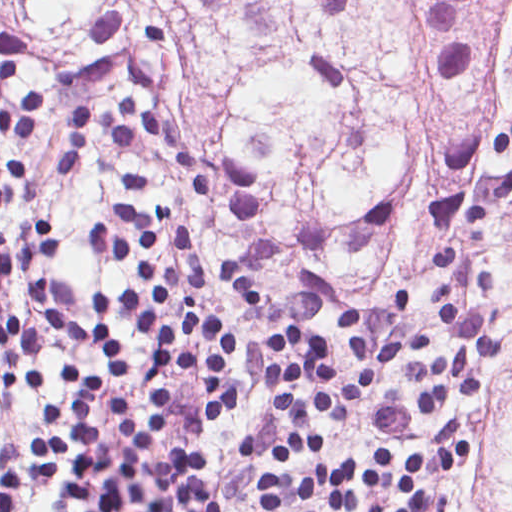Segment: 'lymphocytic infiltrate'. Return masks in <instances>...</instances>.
<instances>
[{
  "label": "lymphocytic infiltrate",
  "instance_id": "lymphocytic-infiltrate-1",
  "mask_svg": "<svg viewBox=\"0 0 512 512\" xmlns=\"http://www.w3.org/2000/svg\"><path fill=\"white\" fill-rule=\"evenodd\" d=\"M25 40L0 33V134H29L37 127L43 94L9 92L19 77ZM101 129L112 145L134 147L148 133L166 157L183 172L192 192L212 197V172L192 139L180 126L140 103L125 90L111 104L78 100L64 112L59 132V175L82 164L90 133ZM35 198V184L19 159L0 158V209ZM112 221L89 233L95 248L138 280L126 287H97L92 308V350L105 357L112 372L126 378L133 364L114 345L118 331L147 336L162 352L164 366L156 378L186 370L207 382L197 410L202 422L226 425L240 411L242 397L232 374L243 356L234 323L208 311L199 301L201 262L189 249L186 235L166 214L110 207ZM53 255V232L40 223L0 227V291L11 271H25ZM436 284L452 348L446 357L409 364L420 381L415 412L429 414L448 400H475L484 389L485 358L500 347L493 328L495 306L477 299V289L499 287L476 267L465 245H444L424 256L420 265ZM341 327L357 372L347 378L336 369L330 344L302 326L273 329L265 336L270 382L282 428L271 459L279 466L257 488L258 511L246 505L233 512H428L430 493L418 484L426 462L410 452L402 471L408 507H368L359 491H371L393 465V454L372 450V470L361 462L340 460L331 472H306L299 482L285 475L290 464L323 451V440L311 434L317 415L331 420L351 417L377 387L402 349L434 347L428 328H413L391 340L372 360L362 329V316L341 312ZM3 378L12 393H26L42 383V336L18 315L0 316ZM103 380L78 376L68 405V423L80 462L64 498L71 512H222L215 494L202 479L206 455L193 442H172L167 453L149 456L147 446L162 435L169 412L165 388L156 398V422L142 426L135 417L133 394L112 392L109 413L118 426V441L109 448L90 428L87 407ZM40 433V432H39ZM38 433V434H39ZM38 434L31 440L37 479L51 484L63 469V440ZM21 473L0 471V512H21ZM219 503V501H218ZM220 504V503H219Z\"/></svg>",
  "mask_w": 512,
  "mask_h": 512
}]
</instances>
